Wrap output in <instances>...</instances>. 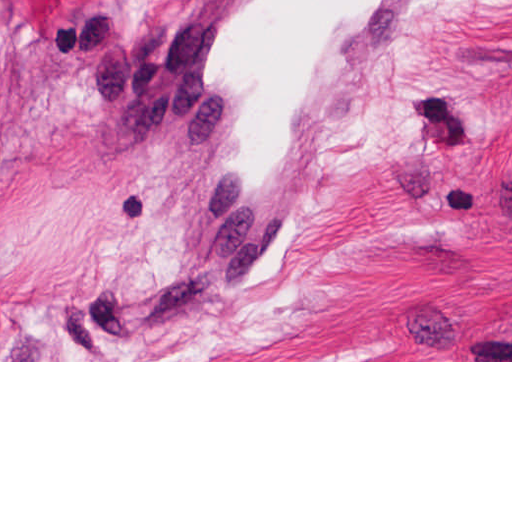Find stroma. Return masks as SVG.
<instances>
[{
	"instance_id": "obj_1",
	"label": "stroma",
	"mask_w": 512,
	"mask_h": 512,
	"mask_svg": "<svg viewBox=\"0 0 512 512\" xmlns=\"http://www.w3.org/2000/svg\"><path fill=\"white\" fill-rule=\"evenodd\" d=\"M0 0V362H512V0H427L298 240L223 302L157 28Z\"/></svg>"
}]
</instances>
